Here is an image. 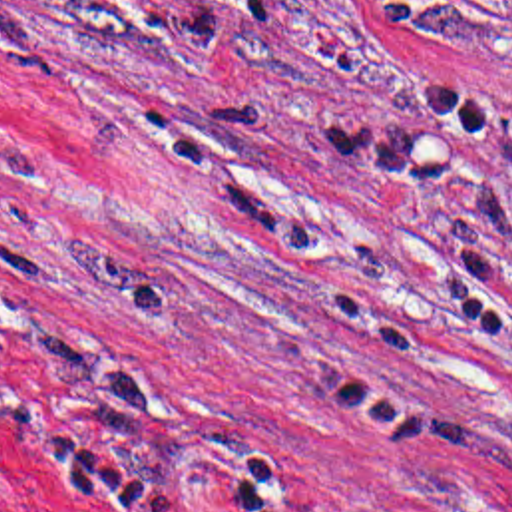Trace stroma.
<instances>
[{"instance_id":"obj_1","label":"stroma","mask_w":512,"mask_h":512,"mask_svg":"<svg viewBox=\"0 0 512 512\" xmlns=\"http://www.w3.org/2000/svg\"><path fill=\"white\" fill-rule=\"evenodd\" d=\"M0 512H512V0H0Z\"/></svg>"}]
</instances>
